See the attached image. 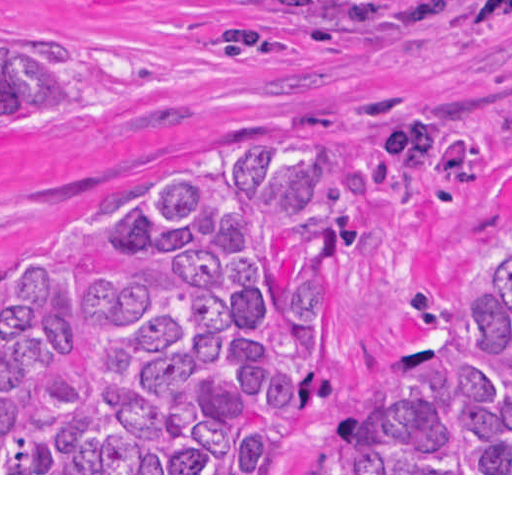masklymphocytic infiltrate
I'll return each mask as SVG.
<instances>
[{
	"label": "lymphocytic infiltrate",
	"instance_id": "lymphocytic-infiltrate-1",
	"mask_svg": "<svg viewBox=\"0 0 512 512\" xmlns=\"http://www.w3.org/2000/svg\"><path fill=\"white\" fill-rule=\"evenodd\" d=\"M487 20H512V12L505 14H494L474 6L473 9L467 13L459 23L465 25H478Z\"/></svg>",
	"mask_w": 512,
	"mask_h": 512
}]
</instances>
